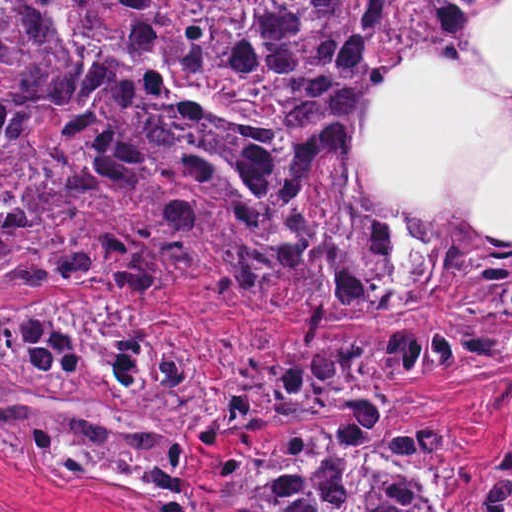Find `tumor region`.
<instances>
[{"label":"tumor region","mask_w":512,"mask_h":512,"mask_svg":"<svg viewBox=\"0 0 512 512\" xmlns=\"http://www.w3.org/2000/svg\"><path fill=\"white\" fill-rule=\"evenodd\" d=\"M500 1H1V294L235 303L297 336L408 331L405 376L512 369V89L467 55ZM200 348L109 300L1 305V464L208 512L199 448L340 417L213 469L223 512H445L469 484L353 341ZM383 417L391 418L381 426ZM512 512V455L476 495Z\"/></svg>","instance_id":"obj_1"}]
</instances>
